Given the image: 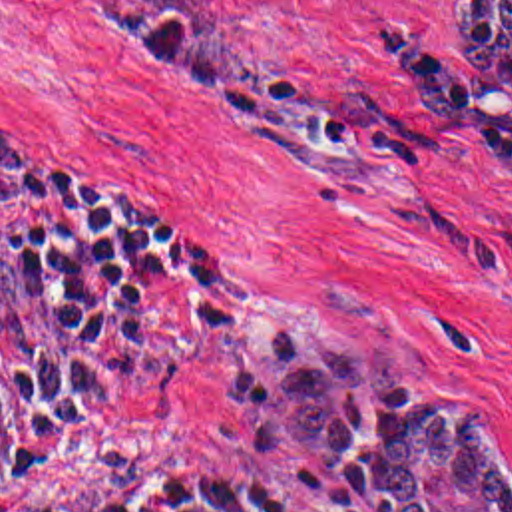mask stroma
<instances>
[{
    "mask_svg": "<svg viewBox=\"0 0 512 512\" xmlns=\"http://www.w3.org/2000/svg\"><path fill=\"white\" fill-rule=\"evenodd\" d=\"M456 0H223L265 77L227 109L85 0H0V127L131 189L221 270L173 280L87 386L30 483L48 512H127L153 481L257 469L340 512L342 475L253 460L227 366L263 328L392 342L408 390L464 392L512 460V91L452 45Z\"/></svg>",
    "mask_w": 512,
    "mask_h": 512,
    "instance_id": "obj_1",
    "label": "stroma"
}]
</instances>
